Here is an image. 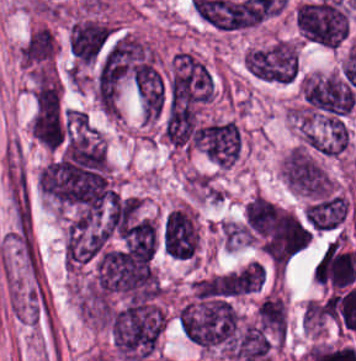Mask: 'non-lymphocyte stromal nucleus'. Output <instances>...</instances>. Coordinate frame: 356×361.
<instances>
[{"label":"non-lymphocyte stromal nucleus","mask_w":356,"mask_h":361,"mask_svg":"<svg viewBox=\"0 0 356 361\" xmlns=\"http://www.w3.org/2000/svg\"><path fill=\"white\" fill-rule=\"evenodd\" d=\"M2 181L13 243H32L33 218L28 175L21 144L8 139L2 148Z\"/></svg>","instance_id":"obj_1"}]
</instances>
